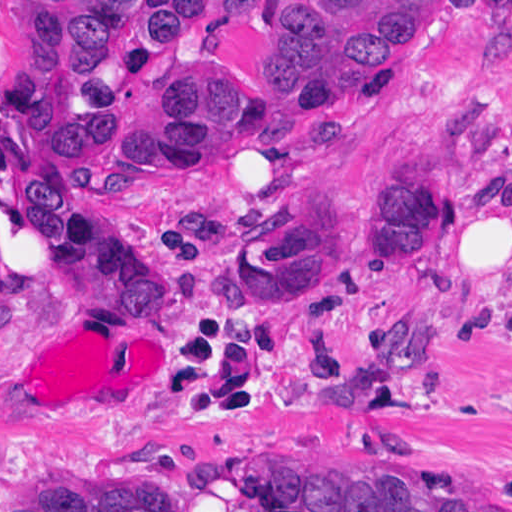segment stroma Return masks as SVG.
<instances>
[{
  "instance_id": "1",
  "label": "stroma",
  "mask_w": 512,
  "mask_h": 512,
  "mask_svg": "<svg viewBox=\"0 0 512 512\" xmlns=\"http://www.w3.org/2000/svg\"><path fill=\"white\" fill-rule=\"evenodd\" d=\"M32 0H0V39ZM285 0H244L121 77L229 54L261 70ZM422 142L444 196L428 254L390 271L347 214L364 173ZM59 155L141 261L173 281L164 320L123 304L76 311L62 262L20 200L28 161ZM512 0H403L358 102L295 138L144 149L98 164L68 127L42 148L6 143L0 107V512L36 474L70 466L152 472L188 512H265L223 475L208 489L129 452L209 458L326 441H404L461 482L512 492ZM302 186L329 199L344 266L323 291L255 297L235 250ZM411 270V271H410ZM429 311L437 359L359 408L311 406L274 386L351 380L389 312Z\"/></svg>"
}]
</instances>
